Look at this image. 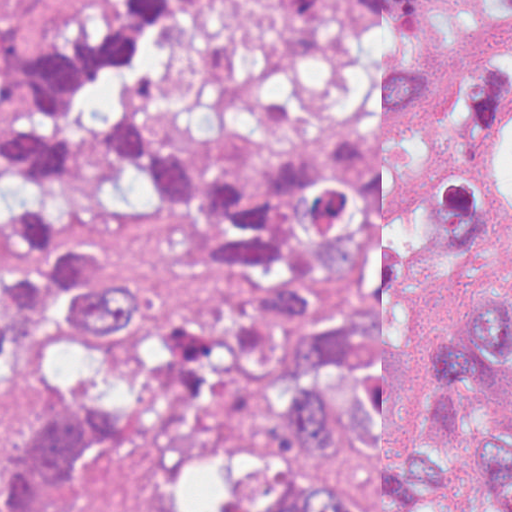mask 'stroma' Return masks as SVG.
Masks as SVG:
<instances>
[{
	"instance_id": "35a3bbf8",
	"label": "stroma",
	"mask_w": 512,
	"mask_h": 512,
	"mask_svg": "<svg viewBox=\"0 0 512 512\" xmlns=\"http://www.w3.org/2000/svg\"><path fill=\"white\" fill-rule=\"evenodd\" d=\"M11 19L40 31L78 34L96 28L122 0H0ZM29 429V406L0 388V457ZM512 425L473 420L461 436L405 441L395 448H433L449 457V511L481 512L476 450L482 436ZM301 457L248 454L193 436H136L72 457L35 512H124L146 502L172 512H271L280 485L298 475L325 473L348 506L376 505L380 457Z\"/></svg>"
}]
</instances>
